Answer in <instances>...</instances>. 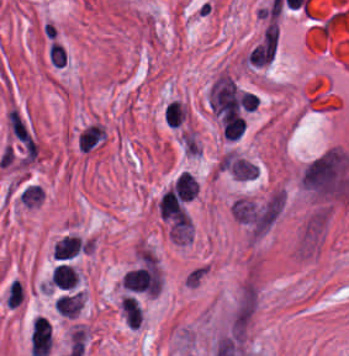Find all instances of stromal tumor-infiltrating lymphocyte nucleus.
<instances>
[{
  "label": "stromal tumor-infiltrating lymphocyte nucleus",
  "mask_w": 349,
  "mask_h": 356,
  "mask_svg": "<svg viewBox=\"0 0 349 356\" xmlns=\"http://www.w3.org/2000/svg\"><path fill=\"white\" fill-rule=\"evenodd\" d=\"M78 279L77 274L67 263H59L52 268L51 281L57 287L70 289Z\"/></svg>",
  "instance_id": "obj_1"
},
{
  "label": "stromal tumor-infiltrating lymphocyte nucleus",
  "mask_w": 349,
  "mask_h": 356,
  "mask_svg": "<svg viewBox=\"0 0 349 356\" xmlns=\"http://www.w3.org/2000/svg\"><path fill=\"white\" fill-rule=\"evenodd\" d=\"M244 122L242 116H228L221 121V131L226 139H237L243 133Z\"/></svg>",
  "instance_id": "obj_2"
},
{
  "label": "stromal tumor-infiltrating lymphocyte nucleus",
  "mask_w": 349,
  "mask_h": 356,
  "mask_svg": "<svg viewBox=\"0 0 349 356\" xmlns=\"http://www.w3.org/2000/svg\"><path fill=\"white\" fill-rule=\"evenodd\" d=\"M185 111L178 101L175 99L169 101L163 113V118L166 125L177 126L184 120Z\"/></svg>",
  "instance_id": "obj_3"
}]
</instances>
